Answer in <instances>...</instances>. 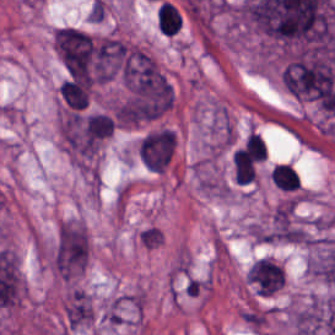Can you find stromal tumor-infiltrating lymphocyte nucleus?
<instances>
[{
  "label": "stromal tumor-infiltrating lymphocyte nucleus",
  "instance_id": "obj_1",
  "mask_svg": "<svg viewBox=\"0 0 335 335\" xmlns=\"http://www.w3.org/2000/svg\"><path fill=\"white\" fill-rule=\"evenodd\" d=\"M157 27L164 35H171L179 30L178 10L167 2L158 4L156 11Z\"/></svg>",
  "mask_w": 335,
  "mask_h": 335
}]
</instances>
